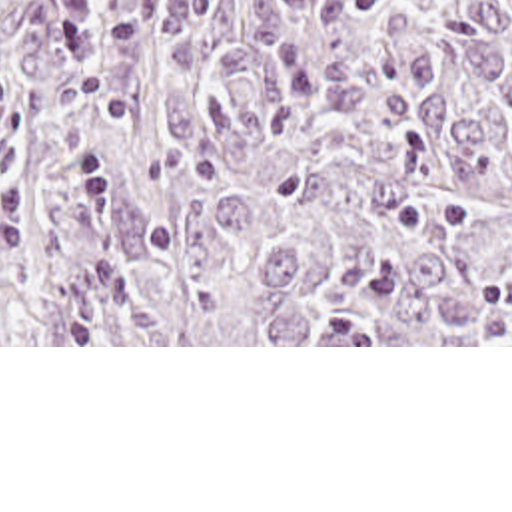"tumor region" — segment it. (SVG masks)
I'll use <instances>...</instances> for the list:
<instances>
[{
  "instance_id": "1",
  "label": "tumor region",
  "mask_w": 512,
  "mask_h": 512,
  "mask_svg": "<svg viewBox=\"0 0 512 512\" xmlns=\"http://www.w3.org/2000/svg\"><path fill=\"white\" fill-rule=\"evenodd\" d=\"M0 345H512V0H0Z\"/></svg>"
}]
</instances>
